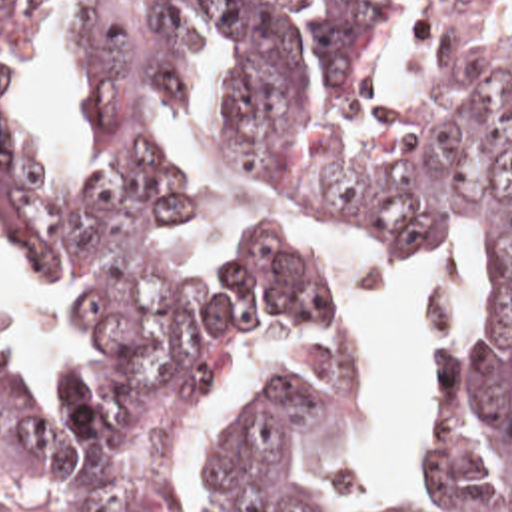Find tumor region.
Returning <instances> with one entry per match:
<instances>
[{
  "label": "tumor region",
  "mask_w": 512,
  "mask_h": 512,
  "mask_svg": "<svg viewBox=\"0 0 512 512\" xmlns=\"http://www.w3.org/2000/svg\"><path fill=\"white\" fill-rule=\"evenodd\" d=\"M55 1L79 15L97 193L59 199L0 115V255L99 293L101 357L55 415L0 365V468L49 464L69 512H147L205 367L265 323L339 307L299 231L195 281L175 267L191 183L155 131L213 41L235 157L478 261L484 325L448 367L444 482L420 512H512V0H0V87ZM349 375L329 345L293 363L199 512H321L297 458Z\"/></svg>",
  "instance_id": "e687c5a6"
}]
</instances>
